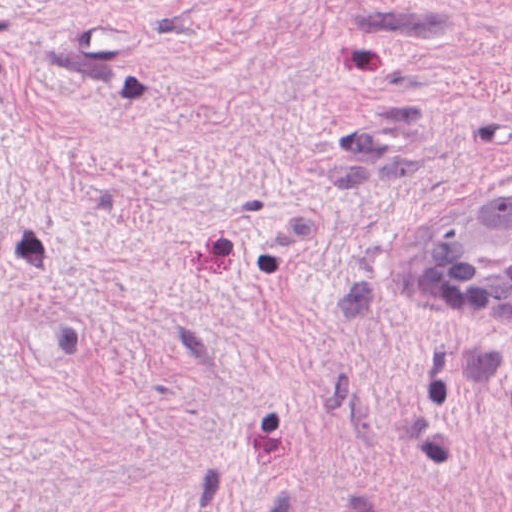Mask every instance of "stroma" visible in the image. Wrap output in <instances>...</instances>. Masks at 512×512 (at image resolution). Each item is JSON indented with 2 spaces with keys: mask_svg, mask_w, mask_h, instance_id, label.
Here are the masks:
<instances>
[{
  "mask_svg": "<svg viewBox=\"0 0 512 512\" xmlns=\"http://www.w3.org/2000/svg\"><path fill=\"white\" fill-rule=\"evenodd\" d=\"M511 184L512 0H0V512H512Z\"/></svg>",
  "mask_w": 512,
  "mask_h": 512,
  "instance_id": "stroma-1",
  "label": "stroma"
}]
</instances>
